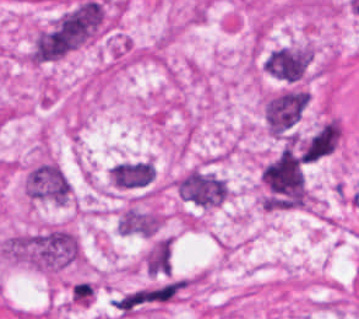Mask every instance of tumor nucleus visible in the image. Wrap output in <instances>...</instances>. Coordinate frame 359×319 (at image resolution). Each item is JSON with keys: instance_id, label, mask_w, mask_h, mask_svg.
Listing matches in <instances>:
<instances>
[{"instance_id": "obj_1", "label": "tumor nucleus", "mask_w": 359, "mask_h": 319, "mask_svg": "<svg viewBox=\"0 0 359 319\" xmlns=\"http://www.w3.org/2000/svg\"><path fill=\"white\" fill-rule=\"evenodd\" d=\"M104 9L99 0H80L48 25L35 37L30 57L35 63L60 58L80 47L102 28Z\"/></svg>"}, {"instance_id": "obj_2", "label": "tumor nucleus", "mask_w": 359, "mask_h": 319, "mask_svg": "<svg viewBox=\"0 0 359 319\" xmlns=\"http://www.w3.org/2000/svg\"><path fill=\"white\" fill-rule=\"evenodd\" d=\"M0 250L12 260L43 270L64 266L77 257L73 233L56 226L16 232L1 242Z\"/></svg>"}, {"instance_id": "obj_3", "label": "tumor nucleus", "mask_w": 359, "mask_h": 319, "mask_svg": "<svg viewBox=\"0 0 359 319\" xmlns=\"http://www.w3.org/2000/svg\"><path fill=\"white\" fill-rule=\"evenodd\" d=\"M259 181L265 209L295 208L307 199L302 164L292 146L286 145L263 164Z\"/></svg>"}, {"instance_id": "obj_4", "label": "tumor nucleus", "mask_w": 359, "mask_h": 319, "mask_svg": "<svg viewBox=\"0 0 359 319\" xmlns=\"http://www.w3.org/2000/svg\"><path fill=\"white\" fill-rule=\"evenodd\" d=\"M308 96L296 87H289L269 95L263 102L264 119L267 131L282 137L299 121Z\"/></svg>"}, {"instance_id": "obj_5", "label": "tumor nucleus", "mask_w": 359, "mask_h": 319, "mask_svg": "<svg viewBox=\"0 0 359 319\" xmlns=\"http://www.w3.org/2000/svg\"><path fill=\"white\" fill-rule=\"evenodd\" d=\"M181 200L212 208L223 203L228 195L226 185L212 172L191 170L175 183Z\"/></svg>"}, {"instance_id": "obj_6", "label": "tumor nucleus", "mask_w": 359, "mask_h": 319, "mask_svg": "<svg viewBox=\"0 0 359 319\" xmlns=\"http://www.w3.org/2000/svg\"><path fill=\"white\" fill-rule=\"evenodd\" d=\"M24 191L30 198L63 204L70 193V184L59 166L42 161L25 175Z\"/></svg>"}, {"instance_id": "obj_7", "label": "tumor nucleus", "mask_w": 359, "mask_h": 319, "mask_svg": "<svg viewBox=\"0 0 359 319\" xmlns=\"http://www.w3.org/2000/svg\"><path fill=\"white\" fill-rule=\"evenodd\" d=\"M313 53L304 46H279L262 59L264 70L281 81H297L305 74Z\"/></svg>"}, {"instance_id": "obj_8", "label": "tumor nucleus", "mask_w": 359, "mask_h": 319, "mask_svg": "<svg viewBox=\"0 0 359 319\" xmlns=\"http://www.w3.org/2000/svg\"><path fill=\"white\" fill-rule=\"evenodd\" d=\"M338 138L339 122L332 117L297 141L298 149L305 162H312L332 153Z\"/></svg>"}, {"instance_id": "obj_9", "label": "tumor nucleus", "mask_w": 359, "mask_h": 319, "mask_svg": "<svg viewBox=\"0 0 359 319\" xmlns=\"http://www.w3.org/2000/svg\"><path fill=\"white\" fill-rule=\"evenodd\" d=\"M150 182V165L145 160H125L111 166V184L118 188H141Z\"/></svg>"}, {"instance_id": "obj_10", "label": "tumor nucleus", "mask_w": 359, "mask_h": 319, "mask_svg": "<svg viewBox=\"0 0 359 319\" xmlns=\"http://www.w3.org/2000/svg\"><path fill=\"white\" fill-rule=\"evenodd\" d=\"M161 223V215L139 209H125L116 222L117 231L129 235L153 236Z\"/></svg>"}, {"instance_id": "obj_11", "label": "tumor nucleus", "mask_w": 359, "mask_h": 319, "mask_svg": "<svg viewBox=\"0 0 359 319\" xmlns=\"http://www.w3.org/2000/svg\"><path fill=\"white\" fill-rule=\"evenodd\" d=\"M172 240L156 238L144 257V266L149 275L161 274L171 268Z\"/></svg>"}]
</instances>
